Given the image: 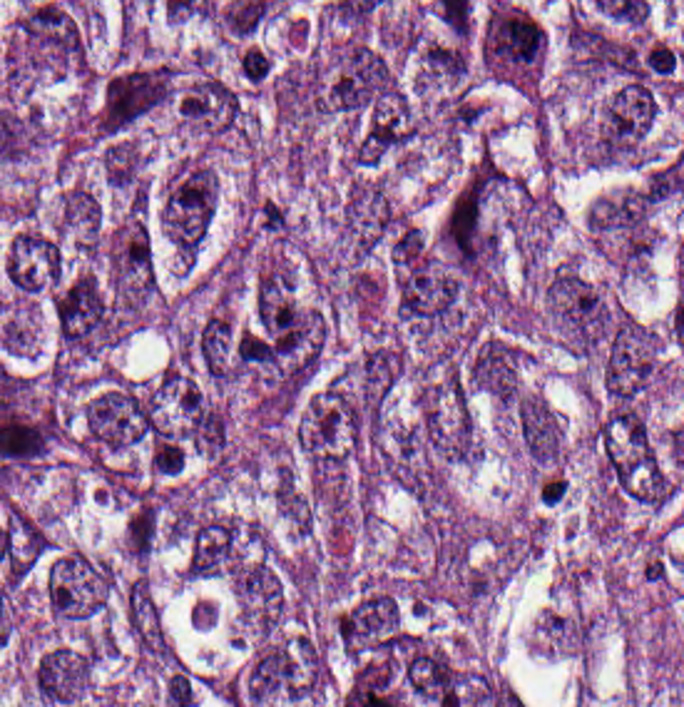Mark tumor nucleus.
Returning a JSON list of instances; mask_svg holds the SVG:
<instances>
[{"label": "tumor nucleus", "instance_id": "2f306a5c", "mask_svg": "<svg viewBox=\"0 0 684 707\" xmlns=\"http://www.w3.org/2000/svg\"><path fill=\"white\" fill-rule=\"evenodd\" d=\"M321 682L316 636L271 632L252 645L233 680L245 707H264L311 695Z\"/></svg>", "mask_w": 684, "mask_h": 707}, {"label": "tumor nucleus", "instance_id": "3d1891a8", "mask_svg": "<svg viewBox=\"0 0 684 707\" xmlns=\"http://www.w3.org/2000/svg\"><path fill=\"white\" fill-rule=\"evenodd\" d=\"M107 588L102 557L85 549H59L48 561L41 595L54 615H95Z\"/></svg>", "mask_w": 684, "mask_h": 707}, {"label": "tumor nucleus", "instance_id": "8087334f", "mask_svg": "<svg viewBox=\"0 0 684 707\" xmlns=\"http://www.w3.org/2000/svg\"><path fill=\"white\" fill-rule=\"evenodd\" d=\"M522 361L515 335L482 333L468 349L464 386L508 406L520 388Z\"/></svg>", "mask_w": 684, "mask_h": 707}, {"label": "tumor nucleus", "instance_id": "feef74b5", "mask_svg": "<svg viewBox=\"0 0 684 707\" xmlns=\"http://www.w3.org/2000/svg\"><path fill=\"white\" fill-rule=\"evenodd\" d=\"M103 184L116 192L144 197V157L137 138L106 136L99 148Z\"/></svg>", "mask_w": 684, "mask_h": 707}, {"label": "tumor nucleus", "instance_id": "5ab6c2c4", "mask_svg": "<svg viewBox=\"0 0 684 707\" xmlns=\"http://www.w3.org/2000/svg\"><path fill=\"white\" fill-rule=\"evenodd\" d=\"M66 267V244L56 227L32 223L15 227L1 259L5 288L26 301L50 299Z\"/></svg>", "mask_w": 684, "mask_h": 707}, {"label": "tumor nucleus", "instance_id": "c2bd9aea", "mask_svg": "<svg viewBox=\"0 0 684 707\" xmlns=\"http://www.w3.org/2000/svg\"><path fill=\"white\" fill-rule=\"evenodd\" d=\"M512 429L528 459L554 467L563 449V426L545 397L522 387L512 405Z\"/></svg>", "mask_w": 684, "mask_h": 707}, {"label": "tumor nucleus", "instance_id": "2083b535", "mask_svg": "<svg viewBox=\"0 0 684 707\" xmlns=\"http://www.w3.org/2000/svg\"><path fill=\"white\" fill-rule=\"evenodd\" d=\"M95 660L80 641H54L35 655L29 676L35 697L49 707H65L82 698Z\"/></svg>", "mask_w": 684, "mask_h": 707}, {"label": "tumor nucleus", "instance_id": "2cbd58db", "mask_svg": "<svg viewBox=\"0 0 684 707\" xmlns=\"http://www.w3.org/2000/svg\"><path fill=\"white\" fill-rule=\"evenodd\" d=\"M246 118L244 96L234 82L207 64H193L176 86V122L218 138L236 134Z\"/></svg>", "mask_w": 684, "mask_h": 707}, {"label": "tumor nucleus", "instance_id": "f7901128", "mask_svg": "<svg viewBox=\"0 0 684 707\" xmlns=\"http://www.w3.org/2000/svg\"><path fill=\"white\" fill-rule=\"evenodd\" d=\"M402 364L403 347L388 338H375L352 362L359 386L372 401L392 386Z\"/></svg>", "mask_w": 684, "mask_h": 707}, {"label": "tumor nucleus", "instance_id": "8643909e", "mask_svg": "<svg viewBox=\"0 0 684 707\" xmlns=\"http://www.w3.org/2000/svg\"><path fill=\"white\" fill-rule=\"evenodd\" d=\"M477 58L494 82H538L545 31L540 21L515 1H489L474 34Z\"/></svg>", "mask_w": 684, "mask_h": 707}, {"label": "tumor nucleus", "instance_id": "3e47fb67", "mask_svg": "<svg viewBox=\"0 0 684 707\" xmlns=\"http://www.w3.org/2000/svg\"><path fill=\"white\" fill-rule=\"evenodd\" d=\"M56 218L71 246H90L98 233L100 205L80 183H66L56 202Z\"/></svg>", "mask_w": 684, "mask_h": 707}]
</instances>
